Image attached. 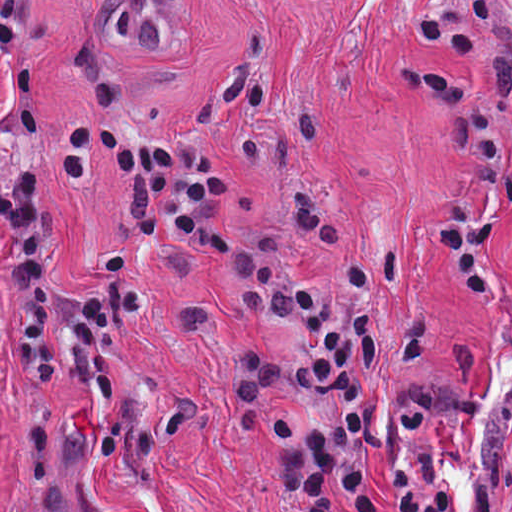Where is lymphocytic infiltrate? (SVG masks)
Listing matches in <instances>:
<instances>
[{
  "instance_id": "f902f5d3",
  "label": "lymphocytic infiltrate",
  "mask_w": 512,
  "mask_h": 512,
  "mask_svg": "<svg viewBox=\"0 0 512 512\" xmlns=\"http://www.w3.org/2000/svg\"><path fill=\"white\" fill-rule=\"evenodd\" d=\"M38 2L0 0V68L15 103L11 177L0 183L12 358L40 347L51 307L46 146L35 111L39 48L31 32ZM412 25L425 45L459 49L495 75L491 93L479 96L451 75L431 79L421 63L400 55L396 76L407 95L432 96L443 114V167L511 138L512 0L503 6L501 0H466L461 13L438 10ZM96 149L127 190V217L107 252L104 278L67 300L63 337L149 299L131 270L132 259L145 248L170 245L216 259L232 245L223 221L230 174L193 132L131 125L92 109L69 113L53 128L49 146V173L61 189L83 184ZM347 210L335 180L293 183L283 239Z\"/></svg>"
}]
</instances>
